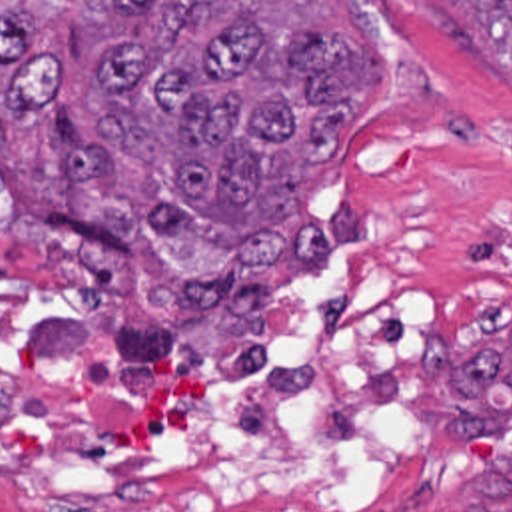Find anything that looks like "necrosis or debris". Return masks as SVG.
Listing matches in <instances>:
<instances>
[{
  "mask_svg": "<svg viewBox=\"0 0 512 512\" xmlns=\"http://www.w3.org/2000/svg\"><path fill=\"white\" fill-rule=\"evenodd\" d=\"M435 356L437 304L353 264L293 280L263 354L0 266V507L403 509Z\"/></svg>",
  "mask_w": 512,
  "mask_h": 512,
  "instance_id": "obj_1",
  "label": "necrosis or debris"
}]
</instances>
